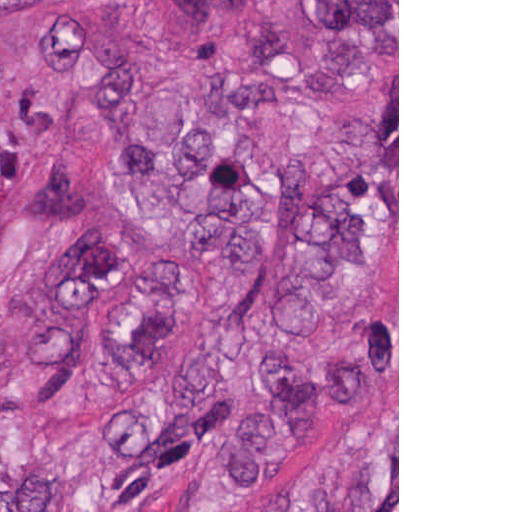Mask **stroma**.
I'll use <instances>...</instances> for the list:
<instances>
[{"label": "stroma", "mask_w": 512, "mask_h": 512, "mask_svg": "<svg viewBox=\"0 0 512 512\" xmlns=\"http://www.w3.org/2000/svg\"><path fill=\"white\" fill-rule=\"evenodd\" d=\"M280 0H240L204 37L184 0H151L139 28L137 62L155 80H173L183 91L209 71L265 74L292 113L329 115L363 123L394 149L397 166V283L379 300L316 328L326 339L345 337L373 318L397 319V361L338 422L306 442L295 459L258 490L225 512H251L288 479L329 454L374 433L397 413V512H399V0L397 45L383 59H299L288 55L279 27ZM74 80L37 75L0 43V135L20 153V185L0 216V414H21L59 432H80L113 419L143 389H127L112 362L117 328L135 297L124 283L101 308L96 354L61 390L39 394L24 381L19 335L57 259L79 237L34 231L25 216V194L43 169L75 159L111 210L136 252L166 255L186 279V337L172 365L223 327L250 300L257 277L243 290L209 283L189 245L156 225L135 202L127 168L116 157L80 154ZM375 169L371 172H376ZM147 385H142L146 387ZM198 478L182 475L162 487L147 512H195Z\"/></svg>", "instance_id": "stroma-1"}]
</instances>
